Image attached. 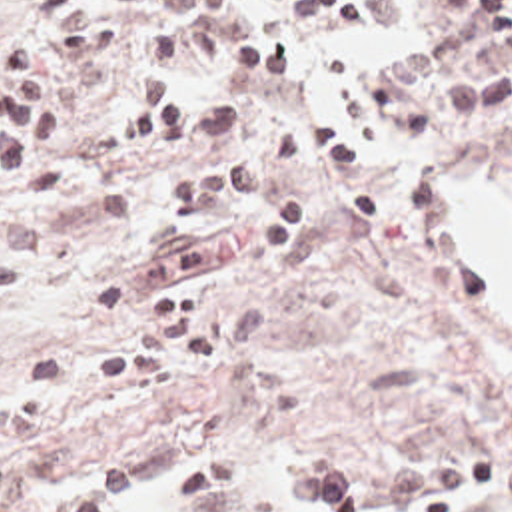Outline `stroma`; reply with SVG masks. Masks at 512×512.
Masks as SVG:
<instances>
[{"label": "stroma", "instance_id": "obj_1", "mask_svg": "<svg viewBox=\"0 0 512 512\" xmlns=\"http://www.w3.org/2000/svg\"><path fill=\"white\" fill-rule=\"evenodd\" d=\"M364 1L368 25L340 41L286 0H250L298 51L280 87L194 59L178 73L240 99V142L264 160L294 119L354 137L352 172L304 180V242L280 262L250 248L242 192L162 214L158 188L188 164L118 146L142 55L32 71L72 174L44 202L0 192V256L23 260V288L0 302V512H300L298 468L342 470L366 496L386 470L446 460L498 462L502 490L476 512H512V388L462 318L512 324L440 266L410 198L512 200V101L424 146L376 141L366 73L446 35L456 0Z\"/></svg>", "mask_w": 512, "mask_h": 512}]
</instances>
